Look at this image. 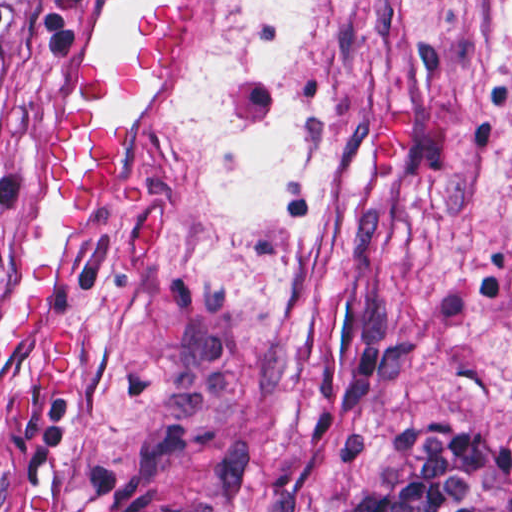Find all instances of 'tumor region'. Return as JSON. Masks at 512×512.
Wrapping results in <instances>:
<instances>
[{
	"instance_id": "1",
	"label": "tumor region",
	"mask_w": 512,
	"mask_h": 512,
	"mask_svg": "<svg viewBox=\"0 0 512 512\" xmlns=\"http://www.w3.org/2000/svg\"><path fill=\"white\" fill-rule=\"evenodd\" d=\"M69 36L67 1H0V206L16 106ZM146 512H512V400L421 426L351 481H322L263 453L176 457L150 486Z\"/></svg>"
}]
</instances>
